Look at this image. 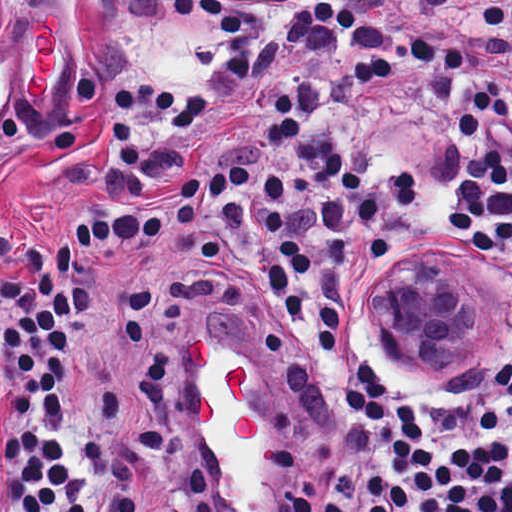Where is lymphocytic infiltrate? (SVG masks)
<instances>
[{"instance_id":"1","label":"lymphocytic infiltrate","mask_w":512,"mask_h":512,"mask_svg":"<svg viewBox=\"0 0 512 512\" xmlns=\"http://www.w3.org/2000/svg\"><path fill=\"white\" fill-rule=\"evenodd\" d=\"M443 256L492 335L423 379L380 301ZM200 356L265 387L286 512H512V0H190L97 205L0 270V512H212Z\"/></svg>"}]
</instances>
